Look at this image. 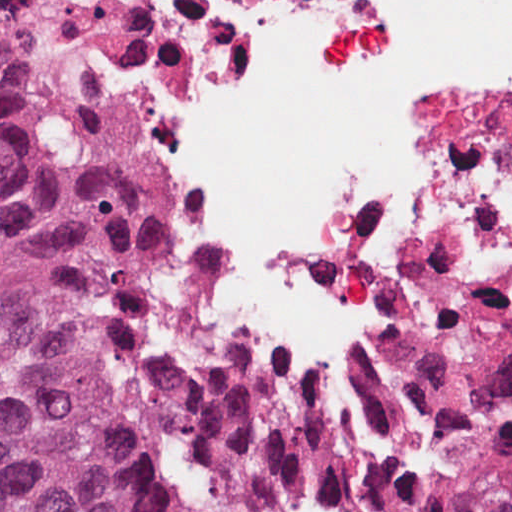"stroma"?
Instances as JSON below:
<instances>
[{"label": "stroma", "instance_id": "stroma-1", "mask_svg": "<svg viewBox=\"0 0 512 512\" xmlns=\"http://www.w3.org/2000/svg\"><path fill=\"white\" fill-rule=\"evenodd\" d=\"M6 5H21L45 13L68 17H98L112 21H135L147 41V214L151 236L162 251L177 278L196 296L207 311L217 329L238 343L219 321L214 308L200 284L190 272L184 254L176 240L175 232L169 217L163 208L158 187L154 181V115L156 108V65L154 53L148 43L142 19L134 14L110 10L98 0H22ZM239 344V343H238ZM241 345V344H239ZM242 346V345H241ZM265 363V362H264ZM267 364V363H266ZM273 370L300 384L314 394L337 414V410L321 393L337 382L319 374L315 370H298L290 367H275L267 364ZM339 415V414H338ZM340 416V415H339ZM386 472L397 482L406 496L420 512H428L425 506L411 490L407 481L396 471L375 458ZM0 512H6L0 487Z\"/></svg>", "mask_w": 512, "mask_h": 512}]
</instances>
